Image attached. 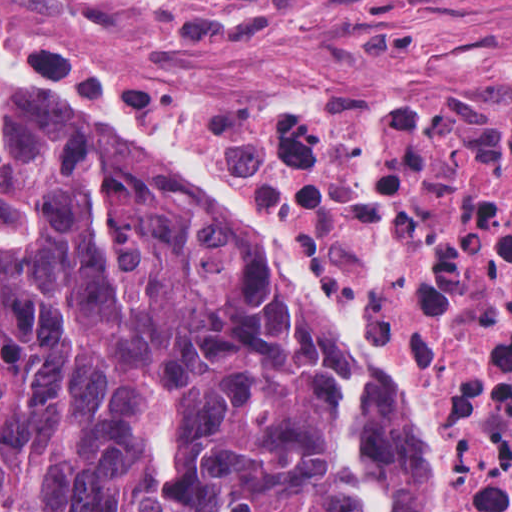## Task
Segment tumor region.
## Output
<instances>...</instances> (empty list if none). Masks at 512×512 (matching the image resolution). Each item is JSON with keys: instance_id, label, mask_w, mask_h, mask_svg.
Listing matches in <instances>:
<instances>
[{"instance_id": "1", "label": "tumor region", "mask_w": 512, "mask_h": 512, "mask_svg": "<svg viewBox=\"0 0 512 512\" xmlns=\"http://www.w3.org/2000/svg\"><path fill=\"white\" fill-rule=\"evenodd\" d=\"M334 377L150 175L0 98V512H349Z\"/></svg>"}]
</instances>
